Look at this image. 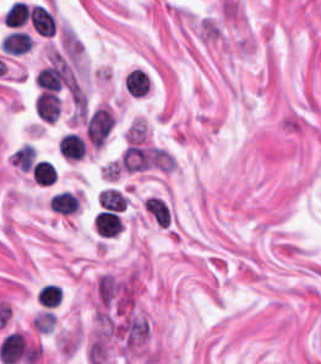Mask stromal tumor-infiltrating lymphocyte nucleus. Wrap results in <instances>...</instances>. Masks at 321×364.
<instances>
[{
    "label": "stromal tumor-infiltrating lymphocyte nucleus",
    "mask_w": 321,
    "mask_h": 364,
    "mask_svg": "<svg viewBox=\"0 0 321 364\" xmlns=\"http://www.w3.org/2000/svg\"><path fill=\"white\" fill-rule=\"evenodd\" d=\"M93 227L98 236L112 238L118 236L123 224L118 214L113 211H100L94 219Z\"/></svg>",
    "instance_id": "stromal-tumor-infiltrating-lymphocyte-nucleus-1"
},
{
    "label": "stromal tumor-infiltrating lymphocyte nucleus",
    "mask_w": 321,
    "mask_h": 364,
    "mask_svg": "<svg viewBox=\"0 0 321 364\" xmlns=\"http://www.w3.org/2000/svg\"><path fill=\"white\" fill-rule=\"evenodd\" d=\"M33 107L39 118L54 121L59 115L60 102L53 91L41 90L33 100Z\"/></svg>",
    "instance_id": "stromal-tumor-infiltrating-lymphocyte-nucleus-2"
},
{
    "label": "stromal tumor-infiltrating lymphocyte nucleus",
    "mask_w": 321,
    "mask_h": 364,
    "mask_svg": "<svg viewBox=\"0 0 321 364\" xmlns=\"http://www.w3.org/2000/svg\"><path fill=\"white\" fill-rule=\"evenodd\" d=\"M59 153L71 159H80L85 155L86 142L74 131H66L59 140Z\"/></svg>",
    "instance_id": "stromal-tumor-infiltrating-lymphocyte-nucleus-3"
},
{
    "label": "stromal tumor-infiltrating lymphocyte nucleus",
    "mask_w": 321,
    "mask_h": 364,
    "mask_svg": "<svg viewBox=\"0 0 321 364\" xmlns=\"http://www.w3.org/2000/svg\"><path fill=\"white\" fill-rule=\"evenodd\" d=\"M28 18L31 26L43 35H51L55 29L54 16L44 5H31Z\"/></svg>",
    "instance_id": "stromal-tumor-infiltrating-lymphocyte-nucleus-4"
},
{
    "label": "stromal tumor-infiltrating lymphocyte nucleus",
    "mask_w": 321,
    "mask_h": 364,
    "mask_svg": "<svg viewBox=\"0 0 321 364\" xmlns=\"http://www.w3.org/2000/svg\"><path fill=\"white\" fill-rule=\"evenodd\" d=\"M32 41L28 32L12 30L5 34L0 41L1 50L11 54H21L31 48Z\"/></svg>",
    "instance_id": "stromal-tumor-infiltrating-lymphocyte-nucleus-5"
},
{
    "label": "stromal tumor-infiltrating lymphocyte nucleus",
    "mask_w": 321,
    "mask_h": 364,
    "mask_svg": "<svg viewBox=\"0 0 321 364\" xmlns=\"http://www.w3.org/2000/svg\"><path fill=\"white\" fill-rule=\"evenodd\" d=\"M150 80L148 76L140 69H133L128 72L124 86L125 91L134 97H144Z\"/></svg>",
    "instance_id": "stromal-tumor-infiltrating-lymphocyte-nucleus-6"
},
{
    "label": "stromal tumor-infiltrating lymphocyte nucleus",
    "mask_w": 321,
    "mask_h": 364,
    "mask_svg": "<svg viewBox=\"0 0 321 364\" xmlns=\"http://www.w3.org/2000/svg\"><path fill=\"white\" fill-rule=\"evenodd\" d=\"M49 205L54 212L72 215L78 209L76 197L67 191L58 192L50 197Z\"/></svg>",
    "instance_id": "stromal-tumor-infiltrating-lymphocyte-nucleus-7"
},
{
    "label": "stromal tumor-infiltrating lymphocyte nucleus",
    "mask_w": 321,
    "mask_h": 364,
    "mask_svg": "<svg viewBox=\"0 0 321 364\" xmlns=\"http://www.w3.org/2000/svg\"><path fill=\"white\" fill-rule=\"evenodd\" d=\"M29 7L22 0H15L3 14L4 24L8 27H20L28 18Z\"/></svg>",
    "instance_id": "stromal-tumor-infiltrating-lymphocyte-nucleus-8"
},
{
    "label": "stromal tumor-infiltrating lymphocyte nucleus",
    "mask_w": 321,
    "mask_h": 364,
    "mask_svg": "<svg viewBox=\"0 0 321 364\" xmlns=\"http://www.w3.org/2000/svg\"><path fill=\"white\" fill-rule=\"evenodd\" d=\"M31 178L38 184L50 185L56 178L53 165L44 158L35 162L32 165Z\"/></svg>",
    "instance_id": "stromal-tumor-infiltrating-lymphocyte-nucleus-9"
},
{
    "label": "stromal tumor-infiltrating lymphocyte nucleus",
    "mask_w": 321,
    "mask_h": 364,
    "mask_svg": "<svg viewBox=\"0 0 321 364\" xmlns=\"http://www.w3.org/2000/svg\"><path fill=\"white\" fill-rule=\"evenodd\" d=\"M98 201L101 207L109 211H121L126 203L125 197L112 188L102 189Z\"/></svg>",
    "instance_id": "stromal-tumor-infiltrating-lymphocyte-nucleus-10"
},
{
    "label": "stromal tumor-infiltrating lymphocyte nucleus",
    "mask_w": 321,
    "mask_h": 364,
    "mask_svg": "<svg viewBox=\"0 0 321 364\" xmlns=\"http://www.w3.org/2000/svg\"><path fill=\"white\" fill-rule=\"evenodd\" d=\"M62 293L59 285L43 284L37 292V302L43 307H56Z\"/></svg>",
    "instance_id": "stromal-tumor-infiltrating-lymphocyte-nucleus-11"
}]
</instances>
